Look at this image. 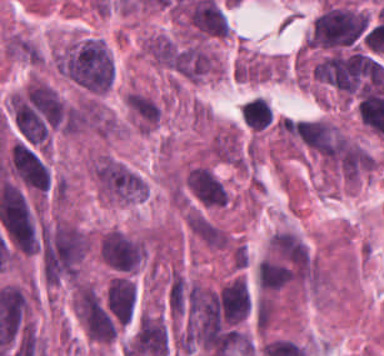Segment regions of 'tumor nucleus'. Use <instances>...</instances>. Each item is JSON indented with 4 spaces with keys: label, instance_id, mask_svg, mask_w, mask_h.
<instances>
[{
    "label": "tumor nucleus",
    "instance_id": "obj_4",
    "mask_svg": "<svg viewBox=\"0 0 384 356\" xmlns=\"http://www.w3.org/2000/svg\"><path fill=\"white\" fill-rule=\"evenodd\" d=\"M73 303L77 318L89 340L98 344H111L118 337L119 326L95 285L78 282Z\"/></svg>",
    "mask_w": 384,
    "mask_h": 356
},
{
    "label": "tumor nucleus",
    "instance_id": "obj_2",
    "mask_svg": "<svg viewBox=\"0 0 384 356\" xmlns=\"http://www.w3.org/2000/svg\"><path fill=\"white\" fill-rule=\"evenodd\" d=\"M89 169L97 194L105 200L115 203H136L143 200L142 177L121 160L96 156Z\"/></svg>",
    "mask_w": 384,
    "mask_h": 356
},
{
    "label": "tumor nucleus",
    "instance_id": "obj_3",
    "mask_svg": "<svg viewBox=\"0 0 384 356\" xmlns=\"http://www.w3.org/2000/svg\"><path fill=\"white\" fill-rule=\"evenodd\" d=\"M366 26L364 11L348 6H329L315 18L305 42L307 46H346L358 38Z\"/></svg>",
    "mask_w": 384,
    "mask_h": 356
},
{
    "label": "tumor nucleus",
    "instance_id": "obj_5",
    "mask_svg": "<svg viewBox=\"0 0 384 356\" xmlns=\"http://www.w3.org/2000/svg\"><path fill=\"white\" fill-rule=\"evenodd\" d=\"M97 252L103 262L118 273H133L144 260V239L112 227L101 234Z\"/></svg>",
    "mask_w": 384,
    "mask_h": 356
},
{
    "label": "tumor nucleus",
    "instance_id": "obj_1",
    "mask_svg": "<svg viewBox=\"0 0 384 356\" xmlns=\"http://www.w3.org/2000/svg\"><path fill=\"white\" fill-rule=\"evenodd\" d=\"M59 70L73 85L104 94L114 84V58L107 44L93 36H73L59 51Z\"/></svg>",
    "mask_w": 384,
    "mask_h": 356
},
{
    "label": "tumor nucleus",
    "instance_id": "obj_6",
    "mask_svg": "<svg viewBox=\"0 0 384 356\" xmlns=\"http://www.w3.org/2000/svg\"><path fill=\"white\" fill-rule=\"evenodd\" d=\"M187 195L202 208L217 209L230 203V192L207 164H193L183 179Z\"/></svg>",
    "mask_w": 384,
    "mask_h": 356
},
{
    "label": "tumor nucleus",
    "instance_id": "obj_9",
    "mask_svg": "<svg viewBox=\"0 0 384 356\" xmlns=\"http://www.w3.org/2000/svg\"><path fill=\"white\" fill-rule=\"evenodd\" d=\"M208 156L219 162L242 167L243 153L237 133L229 130H218L206 148Z\"/></svg>",
    "mask_w": 384,
    "mask_h": 356
},
{
    "label": "tumor nucleus",
    "instance_id": "obj_7",
    "mask_svg": "<svg viewBox=\"0 0 384 356\" xmlns=\"http://www.w3.org/2000/svg\"><path fill=\"white\" fill-rule=\"evenodd\" d=\"M105 296L117 325L123 327L133 319L137 305V288L127 275H113Z\"/></svg>",
    "mask_w": 384,
    "mask_h": 356
},
{
    "label": "tumor nucleus",
    "instance_id": "obj_8",
    "mask_svg": "<svg viewBox=\"0 0 384 356\" xmlns=\"http://www.w3.org/2000/svg\"><path fill=\"white\" fill-rule=\"evenodd\" d=\"M141 52L155 66L172 71L177 69L181 55L172 36L157 31L141 40Z\"/></svg>",
    "mask_w": 384,
    "mask_h": 356
}]
</instances>
